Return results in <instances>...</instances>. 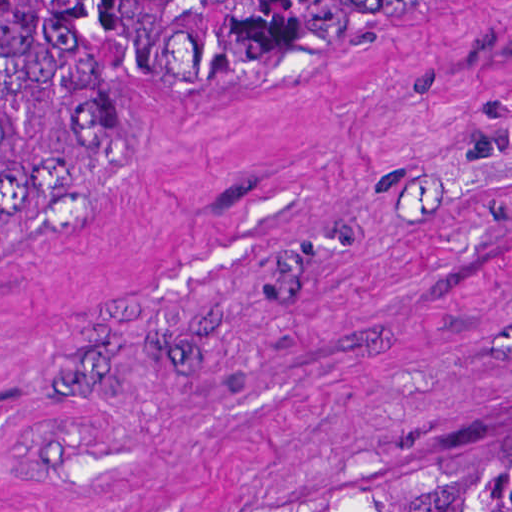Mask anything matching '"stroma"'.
<instances>
[{
    "instance_id": "35a3bbf8",
    "label": "stroma",
    "mask_w": 512,
    "mask_h": 512,
    "mask_svg": "<svg viewBox=\"0 0 512 512\" xmlns=\"http://www.w3.org/2000/svg\"><path fill=\"white\" fill-rule=\"evenodd\" d=\"M512 434V0H367L0 241L18 512H283Z\"/></svg>"
}]
</instances>
